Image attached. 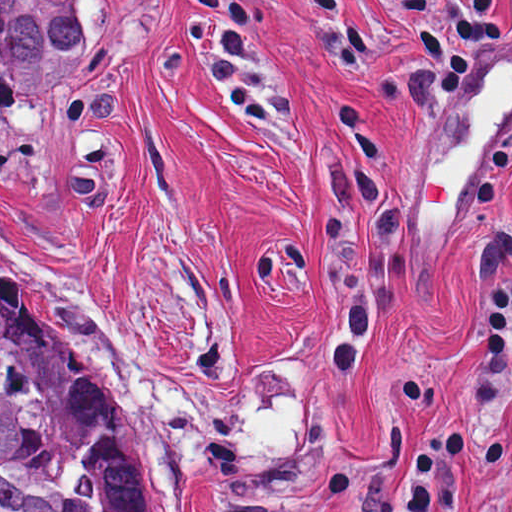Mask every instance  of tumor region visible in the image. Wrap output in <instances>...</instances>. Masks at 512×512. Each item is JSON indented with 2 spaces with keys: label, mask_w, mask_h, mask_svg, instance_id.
<instances>
[{
  "label": "tumor region",
  "mask_w": 512,
  "mask_h": 512,
  "mask_svg": "<svg viewBox=\"0 0 512 512\" xmlns=\"http://www.w3.org/2000/svg\"><path fill=\"white\" fill-rule=\"evenodd\" d=\"M82 46L79 1H0V103L67 78ZM0 512H146L109 390L1 265Z\"/></svg>",
  "instance_id": "1"
}]
</instances>
